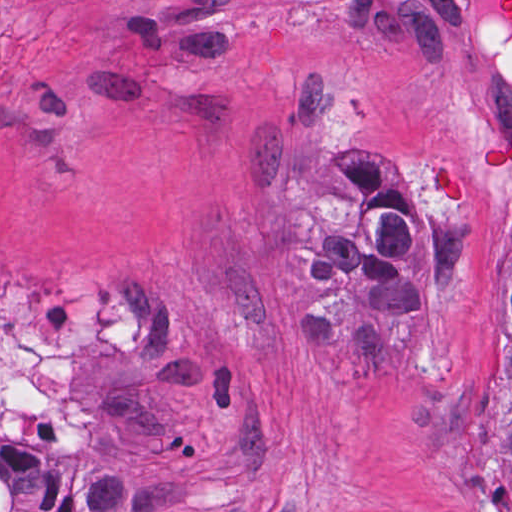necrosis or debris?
Returning <instances> with one entry per match:
<instances>
[{
    "label": "necrosis or debris",
    "instance_id": "obj_1",
    "mask_svg": "<svg viewBox=\"0 0 512 512\" xmlns=\"http://www.w3.org/2000/svg\"><path fill=\"white\" fill-rule=\"evenodd\" d=\"M102 314L64 284L0 290V512H35L77 481L81 407L70 372Z\"/></svg>",
    "mask_w": 512,
    "mask_h": 512
}]
</instances>
